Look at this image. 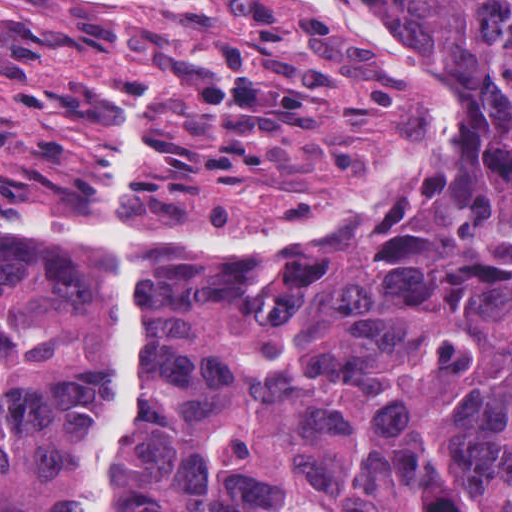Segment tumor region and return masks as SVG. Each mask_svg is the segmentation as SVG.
Listing matches in <instances>:
<instances>
[{
    "instance_id": "tumor-region-1",
    "label": "tumor region",
    "mask_w": 512,
    "mask_h": 512,
    "mask_svg": "<svg viewBox=\"0 0 512 512\" xmlns=\"http://www.w3.org/2000/svg\"><path fill=\"white\" fill-rule=\"evenodd\" d=\"M363 1L458 124L427 211L288 254L0 245V512L87 511L122 243L152 314L117 512H512V0Z\"/></svg>"
}]
</instances>
